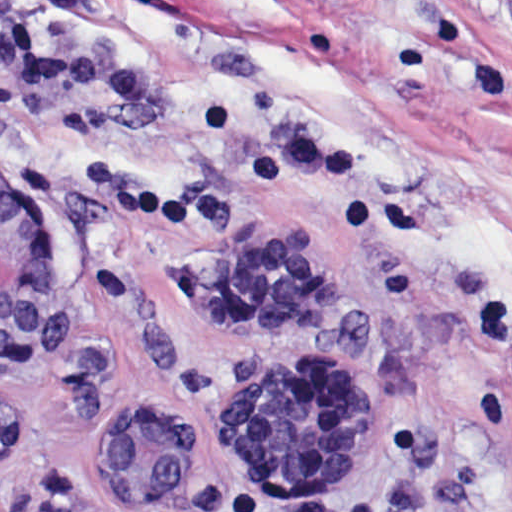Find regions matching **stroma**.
Wrapping results in <instances>:
<instances>
[{
    "instance_id": "stroma-1",
    "label": "stroma",
    "mask_w": 512,
    "mask_h": 512,
    "mask_svg": "<svg viewBox=\"0 0 512 512\" xmlns=\"http://www.w3.org/2000/svg\"><path fill=\"white\" fill-rule=\"evenodd\" d=\"M67 62L151 82L135 106L0 68V176L53 290L0 358L22 443L0 512H512V420L477 416L481 307L512 306V0H15ZM258 363L345 379L370 465L273 496L228 384ZM174 416L224 507L158 508L89 438Z\"/></svg>"
}]
</instances>
